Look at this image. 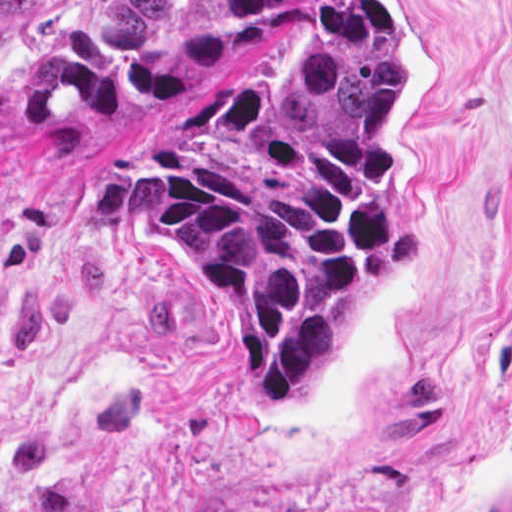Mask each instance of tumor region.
<instances>
[{
  "instance_id": "obj_1",
  "label": "tumor region",
  "mask_w": 512,
  "mask_h": 512,
  "mask_svg": "<svg viewBox=\"0 0 512 512\" xmlns=\"http://www.w3.org/2000/svg\"><path fill=\"white\" fill-rule=\"evenodd\" d=\"M42 1L0 0V95ZM300 2L96 0L2 113L40 133L208 79L180 143L160 125L156 165L131 175L128 207L138 245L213 299L262 416L294 412L343 347L366 282L421 243V228L396 226L403 77L383 4L328 1L283 78L234 71Z\"/></svg>"
}]
</instances>
